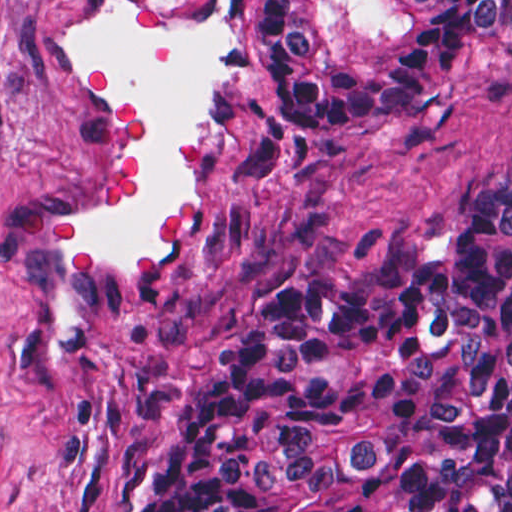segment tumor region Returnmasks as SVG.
Here are the masks:
<instances>
[{
    "mask_svg": "<svg viewBox=\"0 0 512 512\" xmlns=\"http://www.w3.org/2000/svg\"><path fill=\"white\" fill-rule=\"evenodd\" d=\"M505 46L512 0H257L252 111L397 120ZM133 512H512V175L446 254L376 242L263 301Z\"/></svg>",
    "mask_w": 512,
    "mask_h": 512,
    "instance_id": "e687c5a6",
    "label": "tumor region"
}]
</instances>
